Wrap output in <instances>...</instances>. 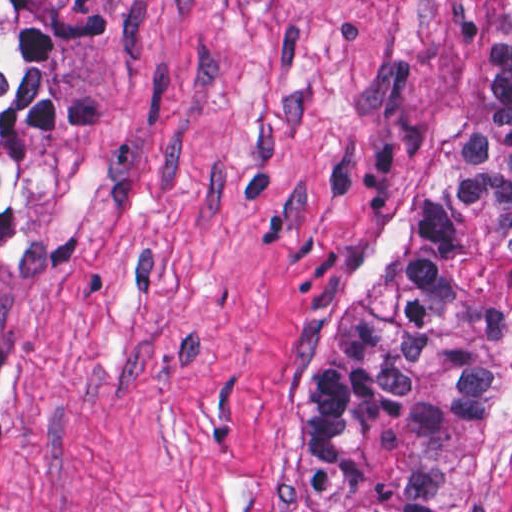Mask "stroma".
<instances>
[{
  "instance_id": "35a3bbf8",
  "label": "stroma",
  "mask_w": 512,
  "mask_h": 512,
  "mask_svg": "<svg viewBox=\"0 0 512 512\" xmlns=\"http://www.w3.org/2000/svg\"><path fill=\"white\" fill-rule=\"evenodd\" d=\"M51 1L108 117L23 143L0 512H296L292 346L449 162L494 0Z\"/></svg>"
}]
</instances>
